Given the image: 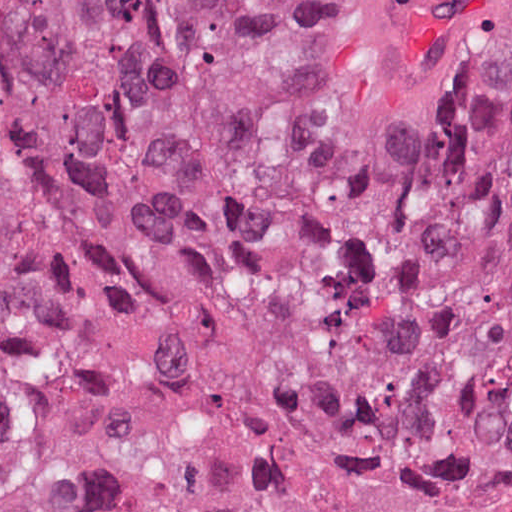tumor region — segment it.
<instances>
[{
  "instance_id": "tumor-region-1",
  "label": "tumor region",
  "mask_w": 512,
  "mask_h": 512,
  "mask_svg": "<svg viewBox=\"0 0 512 512\" xmlns=\"http://www.w3.org/2000/svg\"><path fill=\"white\" fill-rule=\"evenodd\" d=\"M318 0H0V299L163 343L227 300ZM338 392L381 442L512 488V99L347 282ZM0 512H103L74 385L0 364Z\"/></svg>"
}]
</instances>
